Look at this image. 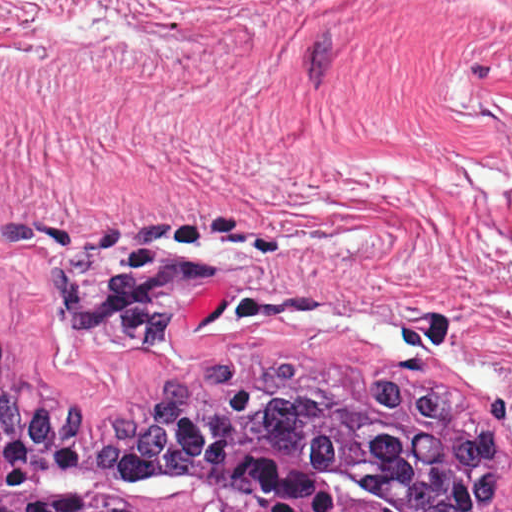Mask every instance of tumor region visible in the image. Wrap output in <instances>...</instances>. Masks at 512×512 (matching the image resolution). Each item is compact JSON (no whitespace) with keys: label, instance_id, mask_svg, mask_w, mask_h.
I'll list each match as a JSON object with an SVG mask.
<instances>
[{"label":"tumor region","instance_id":"tumor-region-1","mask_svg":"<svg viewBox=\"0 0 512 512\" xmlns=\"http://www.w3.org/2000/svg\"><path fill=\"white\" fill-rule=\"evenodd\" d=\"M504 446L461 391L302 359L217 362L131 418L0 335V512H512Z\"/></svg>","mask_w":512,"mask_h":512}]
</instances>
